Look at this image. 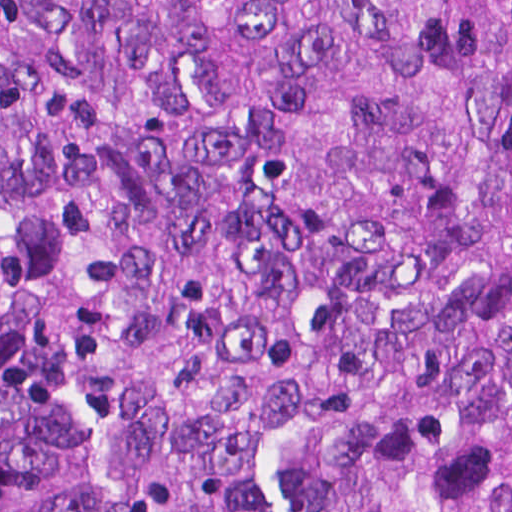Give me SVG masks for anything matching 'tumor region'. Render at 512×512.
<instances>
[{
	"label": "tumor region",
	"instance_id": "1",
	"mask_svg": "<svg viewBox=\"0 0 512 512\" xmlns=\"http://www.w3.org/2000/svg\"><path fill=\"white\" fill-rule=\"evenodd\" d=\"M0 512H512V0H0Z\"/></svg>",
	"mask_w": 512,
	"mask_h": 512
}]
</instances>
